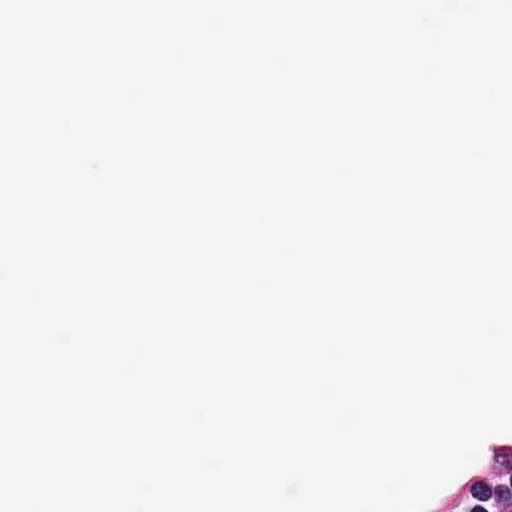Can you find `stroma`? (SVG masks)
I'll return each mask as SVG.
<instances>
[{
	"label": "stroma",
	"instance_id": "stroma-1",
	"mask_svg": "<svg viewBox=\"0 0 512 512\" xmlns=\"http://www.w3.org/2000/svg\"><path fill=\"white\" fill-rule=\"evenodd\" d=\"M512 448V425L494 435L478 437L463 445L457 455L439 468L413 478L386 506L375 512H406L437 486L458 483L475 465L501 450Z\"/></svg>",
	"mask_w": 512,
	"mask_h": 512
}]
</instances>
